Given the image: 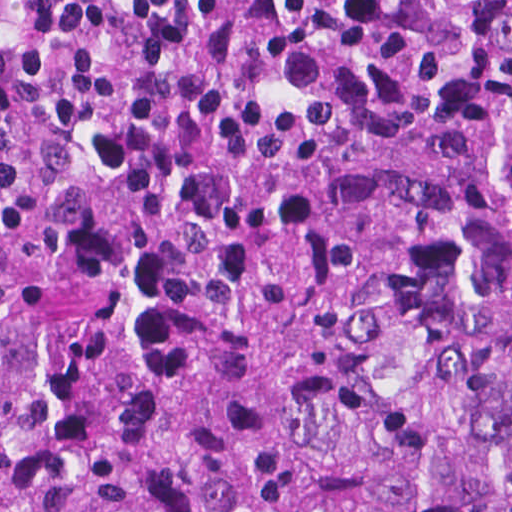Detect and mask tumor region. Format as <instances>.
<instances>
[{
    "label": "tumor region",
    "instance_id": "1",
    "mask_svg": "<svg viewBox=\"0 0 512 512\" xmlns=\"http://www.w3.org/2000/svg\"><path fill=\"white\" fill-rule=\"evenodd\" d=\"M0 512H512V0H0Z\"/></svg>",
    "mask_w": 512,
    "mask_h": 512
}]
</instances>
